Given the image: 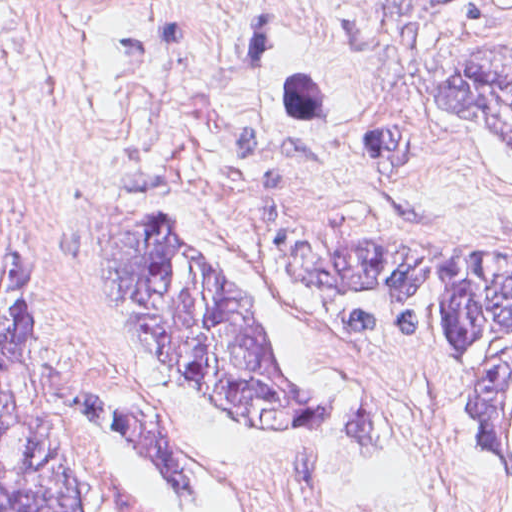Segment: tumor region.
<instances>
[{
    "instance_id": "1",
    "label": "tumor region",
    "mask_w": 512,
    "mask_h": 512,
    "mask_svg": "<svg viewBox=\"0 0 512 512\" xmlns=\"http://www.w3.org/2000/svg\"><path fill=\"white\" fill-rule=\"evenodd\" d=\"M438 106L512 147V51L471 55L434 86ZM62 241L93 259L118 309L245 436H386L368 397L294 392L255 308L172 225L95 189L63 205ZM269 252L321 311L339 353L439 355L476 392L485 488L512 495V241L449 232L376 192H337L290 216ZM78 417L116 425L186 498L209 496L142 396L68 368L60 311L26 290L1 302V512H98ZM237 423L245 426H240Z\"/></svg>"
}]
</instances>
